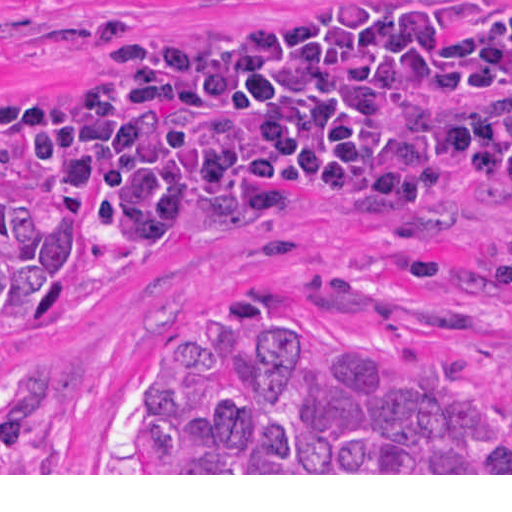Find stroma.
<instances>
[{"mask_svg": "<svg viewBox=\"0 0 512 512\" xmlns=\"http://www.w3.org/2000/svg\"><path fill=\"white\" fill-rule=\"evenodd\" d=\"M300 1L0 0V93L79 85L103 26L243 41ZM0 186L55 200L69 218L75 271L61 321L40 325L44 301L0 302V339L41 351L53 371L26 466L0 475H512L123 473L144 381L178 312L255 288H277L327 334L391 353L512 417V185L474 177L401 212H368L332 194L281 227L158 254L112 246L1 142Z\"/></svg>", "mask_w": 512, "mask_h": 512, "instance_id": "stroma-1", "label": "stroma"}]
</instances>
